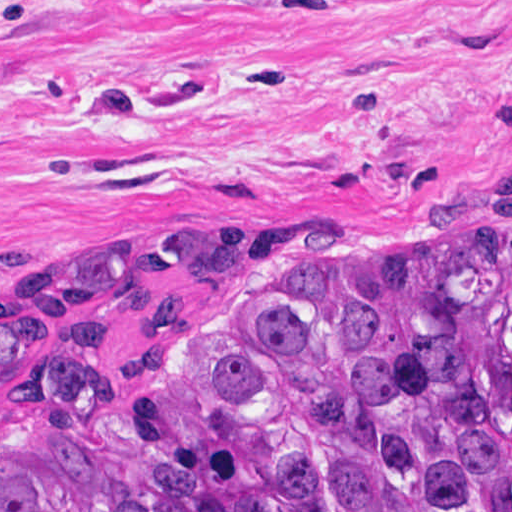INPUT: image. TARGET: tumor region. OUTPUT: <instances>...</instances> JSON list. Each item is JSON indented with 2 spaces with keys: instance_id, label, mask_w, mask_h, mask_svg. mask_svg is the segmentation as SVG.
I'll return each instance as SVG.
<instances>
[{
  "instance_id": "tumor-region-1",
  "label": "tumor region",
  "mask_w": 512,
  "mask_h": 512,
  "mask_svg": "<svg viewBox=\"0 0 512 512\" xmlns=\"http://www.w3.org/2000/svg\"><path fill=\"white\" fill-rule=\"evenodd\" d=\"M0 512H512V181L0 312Z\"/></svg>"
}]
</instances>
